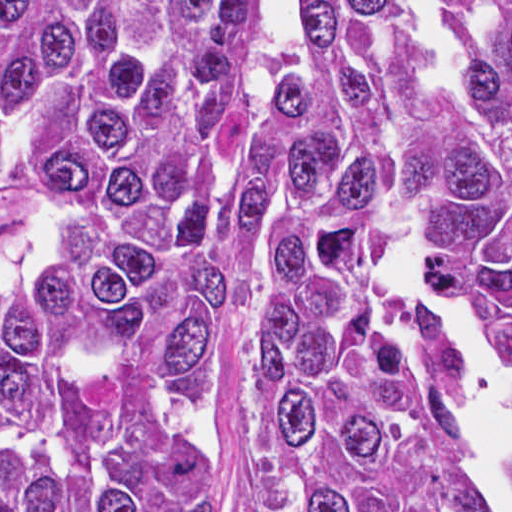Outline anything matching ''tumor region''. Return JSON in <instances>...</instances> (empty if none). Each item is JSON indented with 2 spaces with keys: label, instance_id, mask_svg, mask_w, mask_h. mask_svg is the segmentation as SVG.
<instances>
[{
  "label": "tumor region",
  "instance_id": "obj_1",
  "mask_svg": "<svg viewBox=\"0 0 512 512\" xmlns=\"http://www.w3.org/2000/svg\"><path fill=\"white\" fill-rule=\"evenodd\" d=\"M1 0V512H481L385 261L512 322V0Z\"/></svg>",
  "mask_w": 512,
  "mask_h": 512
}]
</instances>
